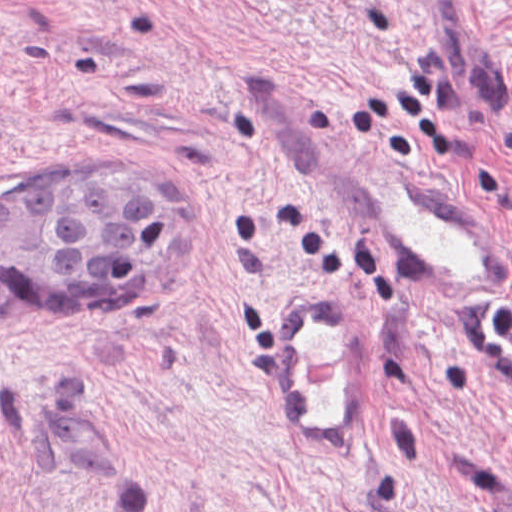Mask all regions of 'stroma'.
<instances>
[{
    "label": "stroma",
    "instance_id": "1",
    "mask_svg": "<svg viewBox=\"0 0 512 512\" xmlns=\"http://www.w3.org/2000/svg\"><path fill=\"white\" fill-rule=\"evenodd\" d=\"M433 181L512 267V0H0V184L173 171L128 293L0 289V512H512V313L445 317L331 165ZM371 319V437L315 451L273 297Z\"/></svg>",
    "mask_w": 512,
    "mask_h": 512
}]
</instances>
